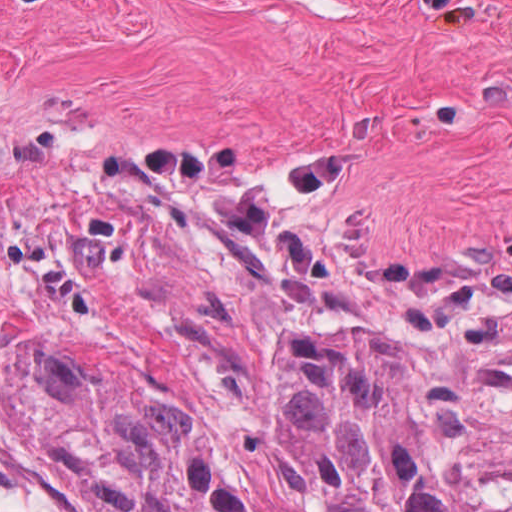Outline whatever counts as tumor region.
I'll list each match as a JSON object with an SVG mask.
<instances>
[{"label":"tumor region","mask_w":512,"mask_h":512,"mask_svg":"<svg viewBox=\"0 0 512 512\" xmlns=\"http://www.w3.org/2000/svg\"><path fill=\"white\" fill-rule=\"evenodd\" d=\"M181 512H512L471 480L442 363Z\"/></svg>","instance_id":"e687c5a6"}]
</instances>
